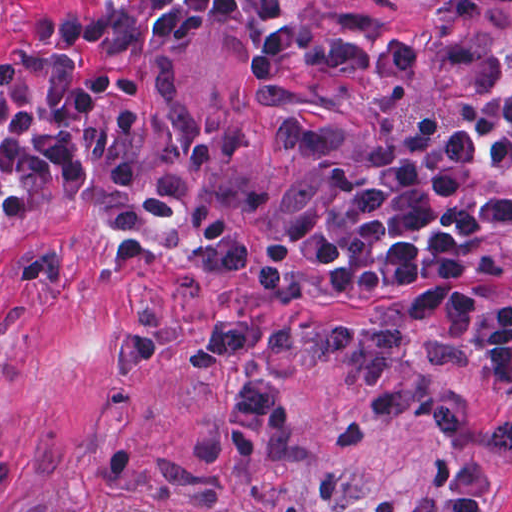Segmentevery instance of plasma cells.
<instances>
[{"label":"plasma cells","mask_w":512,"mask_h":512,"mask_svg":"<svg viewBox=\"0 0 512 512\" xmlns=\"http://www.w3.org/2000/svg\"><path fill=\"white\" fill-rule=\"evenodd\" d=\"M400 318L433 327L467 347L466 372L485 386L512 390V303L491 305L468 284L427 283L405 294ZM189 360L197 371L224 361L241 364L225 433L239 459L285 450L292 416L280 402L270 359L337 357L352 383L368 391L374 419L434 429L453 448L512 459V402L485 401L430 381L416 362L412 335L402 327L350 319H272L243 310L198 327Z\"/></svg>","instance_id":"1"}]
</instances>
